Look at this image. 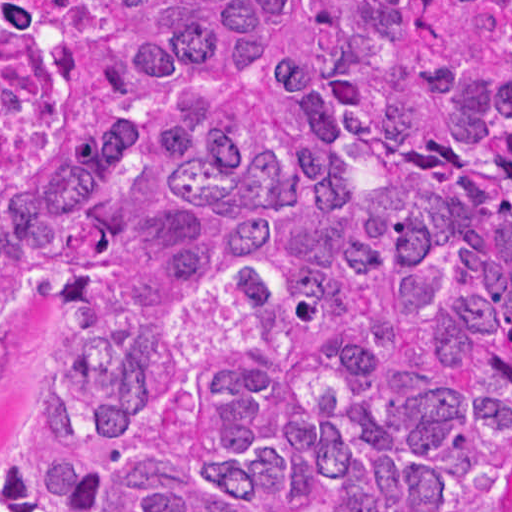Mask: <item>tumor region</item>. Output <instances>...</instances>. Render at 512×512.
<instances>
[{
  "label": "tumor region",
  "instance_id": "tumor-region-1",
  "mask_svg": "<svg viewBox=\"0 0 512 512\" xmlns=\"http://www.w3.org/2000/svg\"><path fill=\"white\" fill-rule=\"evenodd\" d=\"M0 512H499L512 0H0Z\"/></svg>",
  "mask_w": 512,
  "mask_h": 512
}]
</instances>
